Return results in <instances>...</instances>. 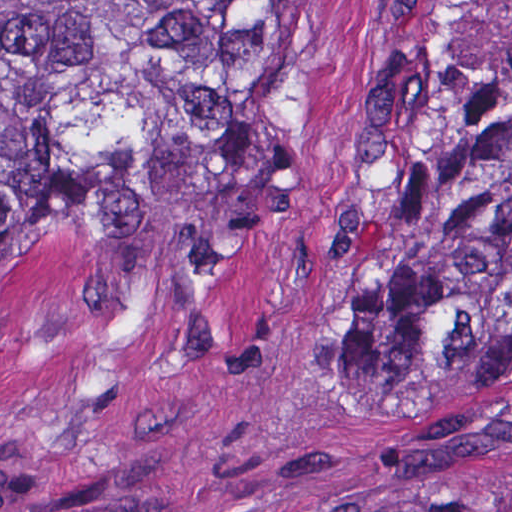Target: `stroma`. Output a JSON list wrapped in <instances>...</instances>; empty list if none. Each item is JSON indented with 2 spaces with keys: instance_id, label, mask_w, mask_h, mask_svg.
Listing matches in <instances>:
<instances>
[{
  "instance_id": "1",
  "label": "stroma",
  "mask_w": 512,
  "mask_h": 512,
  "mask_svg": "<svg viewBox=\"0 0 512 512\" xmlns=\"http://www.w3.org/2000/svg\"><path fill=\"white\" fill-rule=\"evenodd\" d=\"M285 209L263 272L158 290L16 215L0 307V512H512V379H356L358 275L512 0H289Z\"/></svg>"
}]
</instances>
